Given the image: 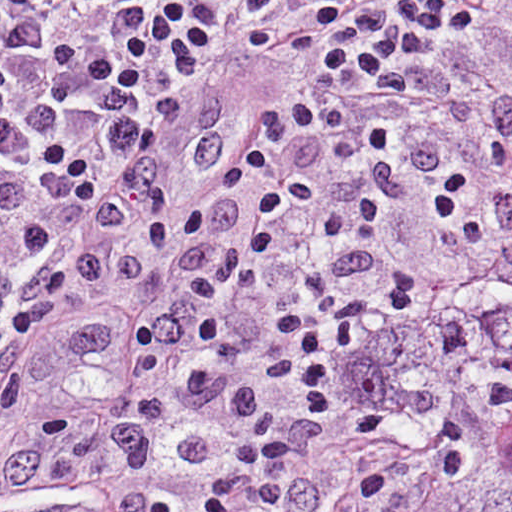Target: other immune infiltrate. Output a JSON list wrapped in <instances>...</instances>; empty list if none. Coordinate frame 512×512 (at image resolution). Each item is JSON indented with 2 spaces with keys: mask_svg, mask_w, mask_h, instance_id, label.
<instances>
[{
  "mask_svg": "<svg viewBox=\"0 0 512 512\" xmlns=\"http://www.w3.org/2000/svg\"><path fill=\"white\" fill-rule=\"evenodd\" d=\"M495 136L512 184V100L497 107ZM438 155L404 112L281 266L206 335L165 359L86 377L119 429L141 512H207L215 447L250 402L299 388L322 403L323 421L380 338L444 288L387 257L383 242ZM435 211L477 251L512 220L494 218L477 169L450 175Z\"/></svg>",
  "mask_w": 512,
  "mask_h": 512,
  "instance_id": "other-immune-infiltrate-1",
  "label": "other immune infiltrate"
}]
</instances>
